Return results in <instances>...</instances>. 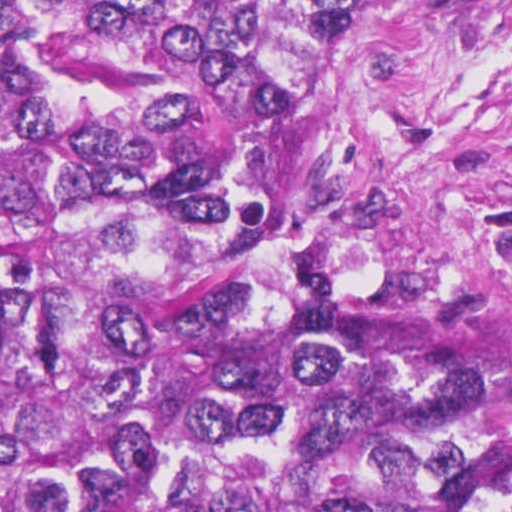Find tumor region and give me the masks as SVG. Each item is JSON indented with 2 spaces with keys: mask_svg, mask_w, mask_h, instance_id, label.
<instances>
[{
  "mask_svg": "<svg viewBox=\"0 0 512 512\" xmlns=\"http://www.w3.org/2000/svg\"><path fill=\"white\" fill-rule=\"evenodd\" d=\"M353 0H0V512H512V386L336 235Z\"/></svg>",
  "mask_w": 512,
  "mask_h": 512,
  "instance_id": "obj_1",
  "label": "tumor region"
}]
</instances>
